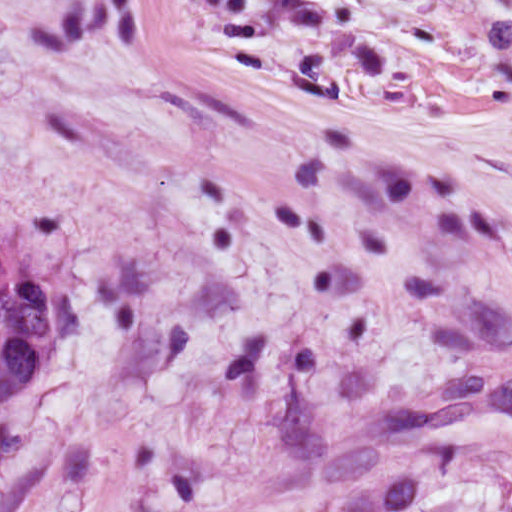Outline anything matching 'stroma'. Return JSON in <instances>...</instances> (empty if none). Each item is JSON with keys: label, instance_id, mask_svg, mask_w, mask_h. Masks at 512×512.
Returning a JSON list of instances; mask_svg holds the SVG:
<instances>
[{"label": "stroma", "instance_id": "obj_1", "mask_svg": "<svg viewBox=\"0 0 512 512\" xmlns=\"http://www.w3.org/2000/svg\"><path fill=\"white\" fill-rule=\"evenodd\" d=\"M84 336L0 512H512V0H261L0 116Z\"/></svg>", "mask_w": 512, "mask_h": 512}]
</instances>
